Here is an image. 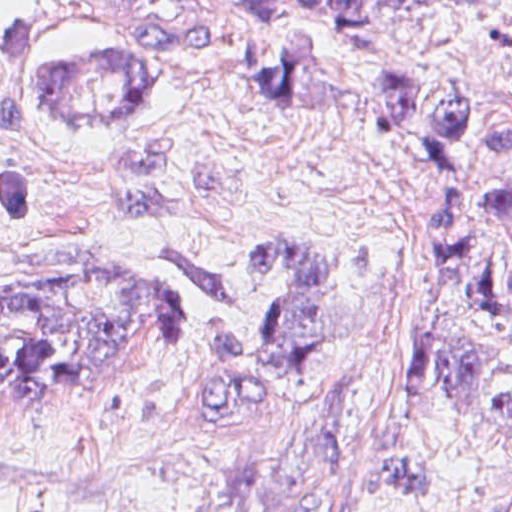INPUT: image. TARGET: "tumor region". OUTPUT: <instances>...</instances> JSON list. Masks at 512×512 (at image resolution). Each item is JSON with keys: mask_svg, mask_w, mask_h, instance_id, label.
<instances>
[{"mask_svg": "<svg viewBox=\"0 0 512 512\" xmlns=\"http://www.w3.org/2000/svg\"><path fill=\"white\" fill-rule=\"evenodd\" d=\"M239 11L274 16L278 0H231ZM311 6L317 0H296ZM475 0H324L345 47L377 42L386 13L451 8ZM0 56L15 84L68 110H144L175 81L122 51L55 53L26 17L0 19ZM310 102L316 73L297 60H243L220 66ZM490 107L481 93L407 60L384 68L381 123L417 158L427 188V223L474 297L499 310L512 305V259L485 242L465 190V145ZM512 158V127L494 146ZM491 204L512 221V179ZM35 187L25 171L0 162V225L34 216ZM0 418L48 408L90 389L106 374L152 367L184 339V319L166 281L123 272L71 295L0 297ZM310 433L272 455L160 512H371V471L352 443ZM496 512H512V505Z\"/></svg>", "mask_w": 512, "mask_h": 512, "instance_id": "obj_1", "label": "tumor region"}]
</instances>
